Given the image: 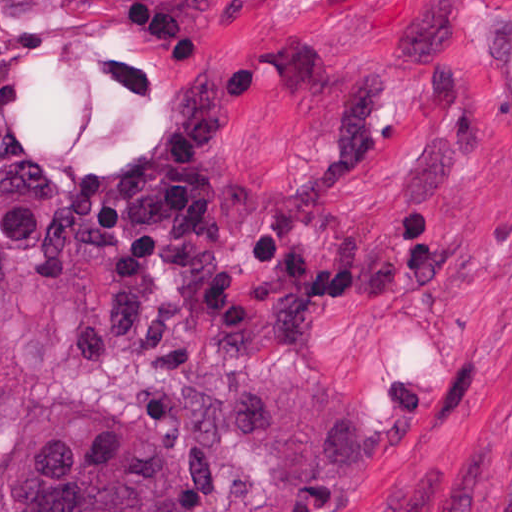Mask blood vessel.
<instances>
[{
	"label": "blood vessel",
	"instance_id": "blood-vessel-1",
	"mask_svg": "<svg viewBox=\"0 0 512 512\" xmlns=\"http://www.w3.org/2000/svg\"><path fill=\"white\" fill-rule=\"evenodd\" d=\"M465 77L471 107L512 175V0L475 21Z\"/></svg>",
	"mask_w": 512,
	"mask_h": 512
}]
</instances>
